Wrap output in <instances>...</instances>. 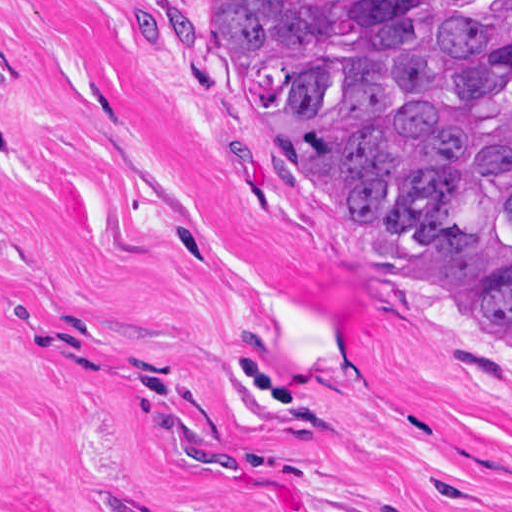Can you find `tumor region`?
<instances>
[{"label": "tumor region", "mask_w": 512, "mask_h": 512, "mask_svg": "<svg viewBox=\"0 0 512 512\" xmlns=\"http://www.w3.org/2000/svg\"><path fill=\"white\" fill-rule=\"evenodd\" d=\"M276 172L512 357V0H160Z\"/></svg>", "instance_id": "1"}]
</instances>
